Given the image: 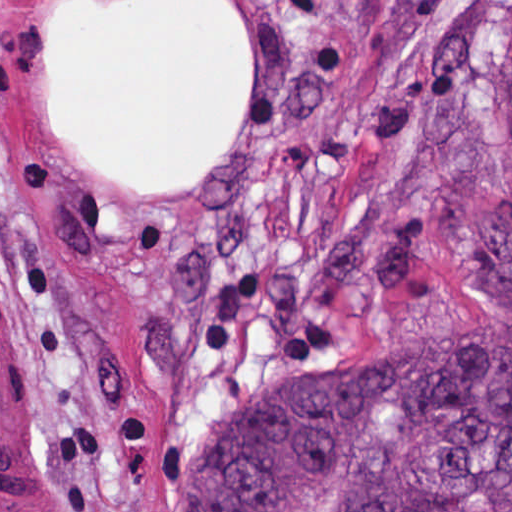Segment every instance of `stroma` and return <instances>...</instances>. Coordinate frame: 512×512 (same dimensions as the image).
I'll return each mask as SVG.
<instances>
[{"label": "stroma", "mask_w": 512, "mask_h": 512, "mask_svg": "<svg viewBox=\"0 0 512 512\" xmlns=\"http://www.w3.org/2000/svg\"><path fill=\"white\" fill-rule=\"evenodd\" d=\"M141 1L0 0V512H158L276 374L512 321V143L480 98L503 0H228L235 143L126 181L50 95L49 49L64 10Z\"/></svg>", "instance_id": "35a3bbf8"}]
</instances>
